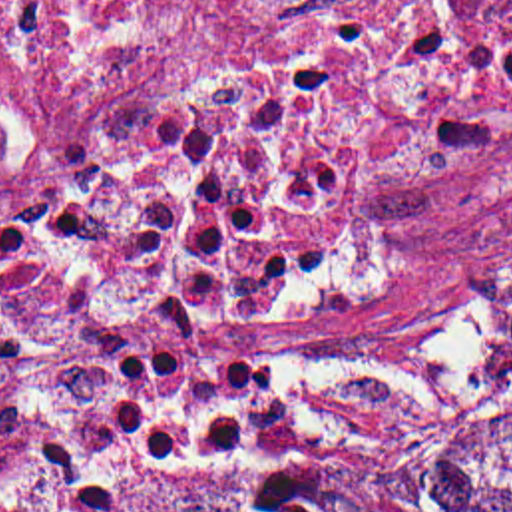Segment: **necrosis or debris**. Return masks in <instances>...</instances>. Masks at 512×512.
I'll use <instances>...</instances> for the list:
<instances>
[{
    "mask_svg": "<svg viewBox=\"0 0 512 512\" xmlns=\"http://www.w3.org/2000/svg\"><path fill=\"white\" fill-rule=\"evenodd\" d=\"M37 185L208 207L254 296L376 227L512 231V0H0V203Z\"/></svg>",
    "mask_w": 512,
    "mask_h": 512,
    "instance_id": "necrosis-or-debris-1",
    "label": "necrosis or debris"
}]
</instances>
